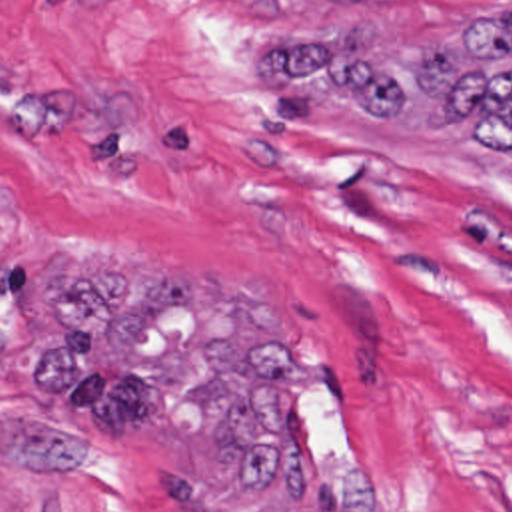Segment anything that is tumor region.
Instances as JSON below:
<instances>
[{"label": "tumor region", "mask_w": 512, "mask_h": 512, "mask_svg": "<svg viewBox=\"0 0 512 512\" xmlns=\"http://www.w3.org/2000/svg\"><path fill=\"white\" fill-rule=\"evenodd\" d=\"M267 45L241 59L263 93L455 135L512 169V5L429 51L377 33ZM67 255L81 259L51 287L57 327L35 347L33 387L71 426L2 411L0 458L77 468L97 436L159 430L211 452L225 490H269L287 512H369V470L317 452L297 426V389L323 353L253 287Z\"/></svg>", "instance_id": "tumor-region-1"}]
</instances>
